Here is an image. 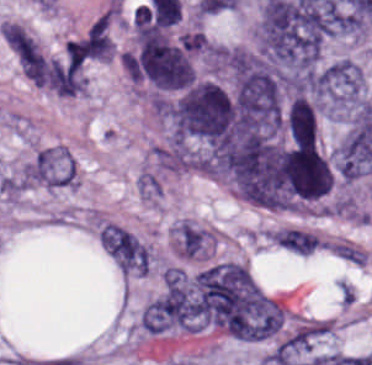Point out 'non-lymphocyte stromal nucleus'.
I'll list each match as a JSON object with an SVG mask.
<instances>
[{"mask_svg":"<svg viewBox=\"0 0 372 365\" xmlns=\"http://www.w3.org/2000/svg\"><path fill=\"white\" fill-rule=\"evenodd\" d=\"M99 244L123 273L145 270V251L136 238L120 226L102 225L97 235Z\"/></svg>","mask_w":372,"mask_h":365,"instance_id":"obj_1","label":"non-lymphocyte stromal nucleus"},{"mask_svg":"<svg viewBox=\"0 0 372 365\" xmlns=\"http://www.w3.org/2000/svg\"><path fill=\"white\" fill-rule=\"evenodd\" d=\"M0 184L3 192L15 196L23 192L27 187L25 182L21 178H17L7 174L1 178Z\"/></svg>","mask_w":372,"mask_h":365,"instance_id":"obj_2","label":"non-lymphocyte stromal nucleus"}]
</instances>
